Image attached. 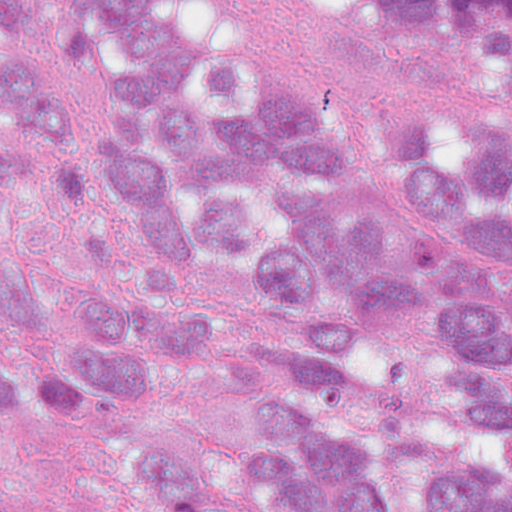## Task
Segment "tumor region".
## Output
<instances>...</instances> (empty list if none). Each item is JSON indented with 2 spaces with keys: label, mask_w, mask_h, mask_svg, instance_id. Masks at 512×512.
<instances>
[{
  "label": "tumor region",
  "mask_w": 512,
  "mask_h": 512,
  "mask_svg": "<svg viewBox=\"0 0 512 512\" xmlns=\"http://www.w3.org/2000/svg\"><path fill=\"white\" fill-rule=\"evenodd\" d=\"M288 0H0V512H512V97L383 115ZM512 62V0H381Z\"/></svg>",
  "instance_id": "tumor-region-1"
}]
</instances>
